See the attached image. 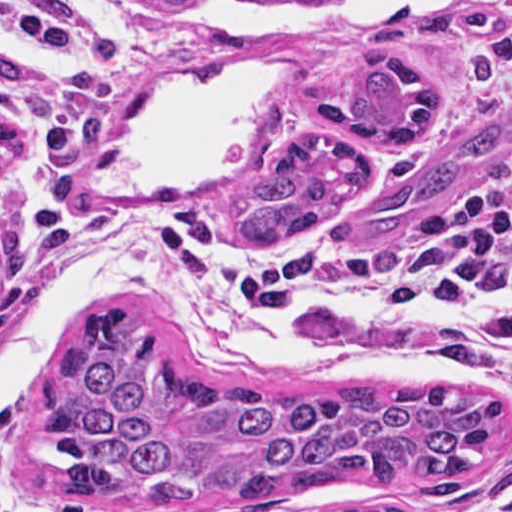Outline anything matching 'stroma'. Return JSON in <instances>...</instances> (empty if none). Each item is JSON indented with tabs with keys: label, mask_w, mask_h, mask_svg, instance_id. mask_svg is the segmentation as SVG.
<instances>
[{
	"label": "stroma",
	"mask_w": 512,
	"mask_h": 512,
	"mask_svg": "<svg viewBox=\"0 0 512 512\" xmlns=\"http://www.w3.org/2000/svg\"><path fill=\"white\" fill-rule=\"evenodd\" d=\"M315 0H255L265 7H302ZM0 3L85 19L114 40V102L88 156L56 168L34 151L29 122L12 118L14 141L0 161V354L28 336L54 291L67 279L72 224L85 186L114 164L159 102L252 59L284 62L276 128L251 166L236 176L187 192L167 206L218 214L229 226L235 209L268 172L282 144L305 130L350 135L376 163V180L401 160L395 143L330 126L317 107L329 74L363 52L404 53L441 79L447 109L422 143L435 151L477 113L512 98V0H430L400 14H373L344 23L274 28L258 35H211L187 26L171 6L143 0H0ZM0 56L23 74L46 79L64 70L58 57L0 28ZM512 193V143L494 163L453 186L398 223L362 229L354 204L273 249L300 240L338 254L356 249L411 252L427 243L439 216L474 202ZM162 208V209H163ZM509 265L512 271V252ZM165 285L194 292L168 283ZM197 293V292H196ZM304 328H368L441 357L434 320L386 317L351 296L309 301L289 315ZM165 358L201 380H230L270 390L332 386L380 388L445 382L496 392L502 431L474 464L454 497L418 492L407 482L340 480L306 495L259 501H158L134 497L85 501L66 487V451L40 427L36 397L0 406L12 440L14 487L29 512L37 501L56 512H330L341 506L394 505L410 512H512V359L503 356L475 380L450 367L430 375H359L321 381L245 375L189 350L177 338L148 327Z\"/></svg>",
	"instance_id": "1"
}]
</instances>
